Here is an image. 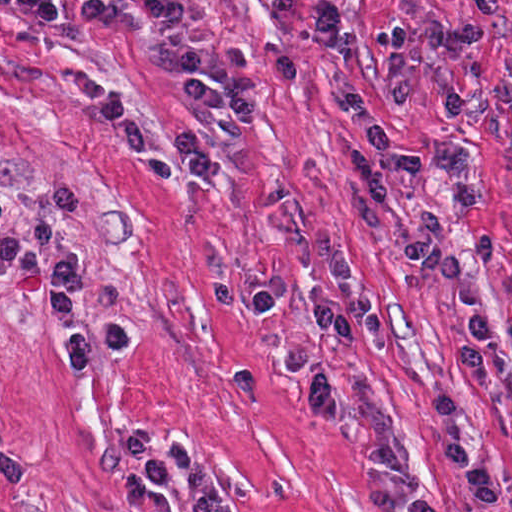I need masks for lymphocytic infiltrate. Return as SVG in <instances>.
I'll return each instance as SVG.
<instances>
[{"mask_svg": "<svg viewBox=\"0 0 512 512\" xmlns=\"http://www.w3.org/2000/svg\"><path fill=\"white\" fill-rule=\"evenodd\" d=\"M279 15H291L297 0H272ZM83 22L109 31H148L161 38L181 79V96L200 121L196 134L177 141L169 160L174 178H210L220 162L225 137L241 125L225 99L224 73L209 61L200 20L189 0H86L75 8ZM80 211L77 187L52 190L44 212L35 220L1 232V285L31 272L40 253L55 239L59 247L46 254V295L49 319L67 369H91L133 345V329L125 320L94 319L88 313V271L75 248L73 229ZM407 263L440 282L449 294L462 332L456 363L472 389H491V331L481 283L467 272L456 240L435 206L420 209L406 250ZM342 303L321 302L314 310L302 343L280 361L279 370L295 386L302 411L318 422H339L345 410L340 376L323 357L328 337L348 349L357 331L341 323ZM433 429L432 479L425 487L415 481V457L398 433L374 441L367 459L382 481L396 488L395 501L384 512H446L433 501H449L445 461L456 466L469 502L484 512L501 508V468L479 445L462 396L435 391L431 402ZM126 448L143 467L146 482L173 483L189 463H201L184 441L177 439L166 455L147 430L132 431Z\"/></svg>", "mask_w": 512, "mask_h": 512, "instance_id": "obj_1", "label": "lymphocytic infiltrate"}]
</instances>
